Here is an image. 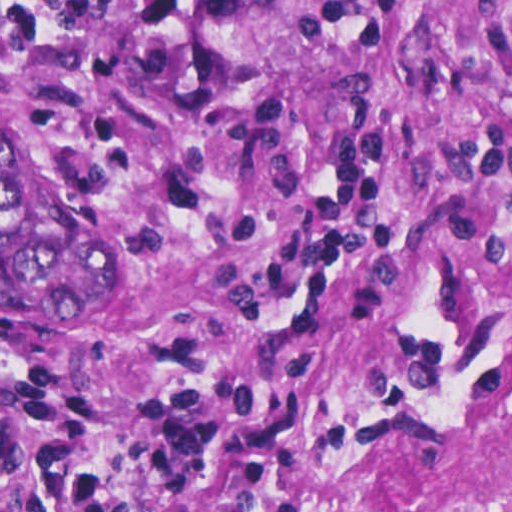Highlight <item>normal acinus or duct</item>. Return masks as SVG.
Segmentation results:
<instances>
[{
  "label": "normal acinus or duct",
  "mask_w": 512,
  "mask_h": 512,
  "mask_svg": "<svg viewBox=\"0 0 512 512\" xmlns=\"http://www.w3.org/2000/svg\"><path fill=\"white\" fill-rule=\"evenodd\" d=\"M85 238L33 155L1 123V306L37 304L69 290Z\"/></svg>",
  "instance_id": "30e58d81"
}]
</instances>
